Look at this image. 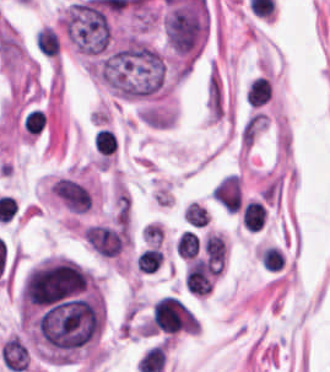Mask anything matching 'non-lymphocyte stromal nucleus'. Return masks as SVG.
Returning a JSON list of instances; mask_svg holds the SVG:
<instances>
[{"mask_svg": "<svg viewBox=\"0 0 330 372\" xmlns=\"http://www.w3.org/2000/svg\"><path fill=\"white\" fill-rule=\"evenodd\" d=\"M207 119L219 120L226 111V97L222 78L216 64L211 65L205 88Z\"/></svg>", "mask_w": 330, "mask_h": 372, "instance_id": "non-lymphocyte-stromal-nucleus-1", "label": "non-lymphocyte stromal nucleus"}, {"mask_svg": "<svg viewBox=\"0 0 330 372\" xmlns=\"http://www.w3.org/2000/svg\"><path fill=\"white\" fill-rule=\"evenodd\" d=\"M212 195L228 211H238L242 206V190L235 173L223 176L213 186Z\"/></svg>", "mask_w": 330, "mask_h": 372, "instance_id": "non-lymphocyte-stromal-nucleus-2", "label": "non-lymphocyte stromal nucleus"}, {"mask_svg": "<svg viewBox=\"0 0 330 372\" xmlns=\"http://www.w3.org/2000/svg\"><path fill=\"white\" fill-rule=\"evenodd\" d=\"M34 43L39 51L49 54H59L60 41L55 31L47 25H43L34 33Z\"/></svg>", "mask_w": 330, "mask_h": 372, "instance_id": "non-lymphocyte-stromal-nucleus-3", "label": "non-lymphocyte stromal nucleus"}]
</instances>
